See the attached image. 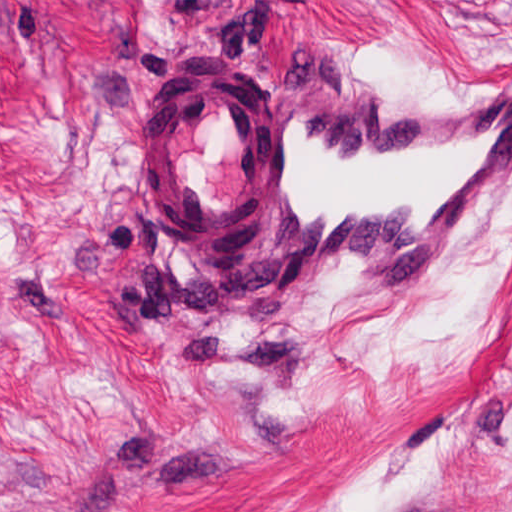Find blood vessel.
Returning a JSON list of instances; mask_svg holds the SVG:
<instances>
[{
  "label": "blood vessel",
  "mask_w": 512,
  "mask_h": 512,
  "mask_svg": "<svg viewBox=\"0 0 512 512\" xmlns=\"http://www.w3.org/2000/svg\"><path fill=\"white\" fill-rule=\"evenodd\" d=\"M512 173V76L371 104L290 63L268 91L217 58L182 71L140 141L160 233L210 283L432 273Z\"/></svg>",
  "instance_id": "obj_1"
}]
</instances>
